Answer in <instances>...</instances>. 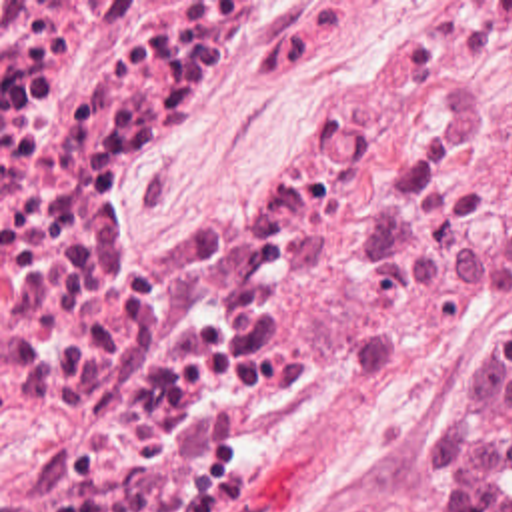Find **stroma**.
<instances>
[{
	"label": "stroma",
	"mask_w": 512,
	"mask_h": 512,
	"mask_svg": "<svg viewBox=\"0 0 512 512\" xmlns=\"http://www.w3.org/2000/svg\"><path fill=\"white\" fill-rule=\"evenodd\" d=\"M456 0H310L294 26L176 104L138 156L162 212H216L282 176L350 92L364 54L396 24ZM512 122V108L504 114ZM290 372L244 406L240 484L198 512H452L432 452L512 310L480 328L418 334L368 310L356 268L302 256L278 308Z\"/></svg>",
	"instance_id": "1"
}]
</instances>
